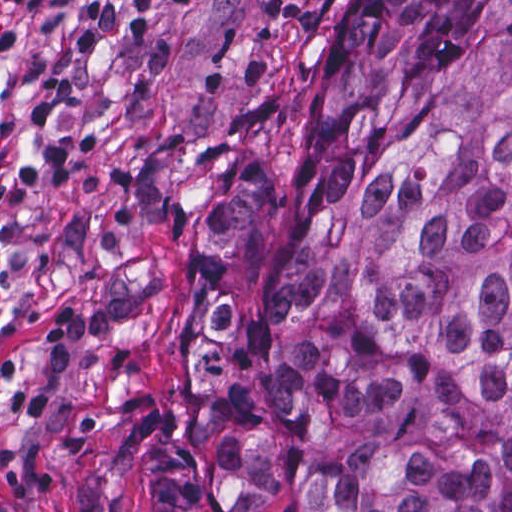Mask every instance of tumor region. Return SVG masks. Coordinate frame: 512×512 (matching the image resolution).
<instances>
[{"instance_id": "obj_1", "label": "tumor region", "mask_w": 512, "mask_h": 512, "mask_svg": "<svg viewBox=\"0 0 512 512\" xmlns=\"http://www.w3.org/2000/svg\"><path fill=\"white\" fill-rule=\"evenodd\" d=\"M342 130L314 233L202 312L143 512H512V0H342L303 131ZM272 200L238 158L205 248Z\"/></svg>"}]
</instances>
